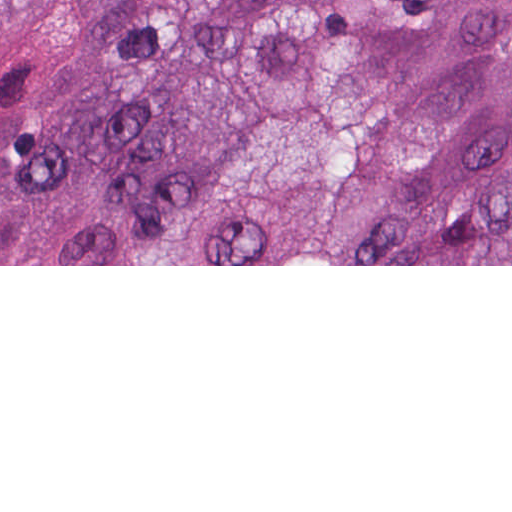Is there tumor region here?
Returning a JSON list of instances; mask_svg holds the SVG:
<instances>
[{
	"instance_id": "1",
	"label": "tumor region",
	"mask_w": 512,
	"mask_h": 512,
	"mask_svg": "<svg viewBox=\"0 0 512 512\" xmlns=\"http://www.w3.org/2000/svg\"><path fill=\"white\" fill-rule=\"evenodd\" d=\"M0 264H512V0H0Z\"/></svg>"
}]
</instances>
